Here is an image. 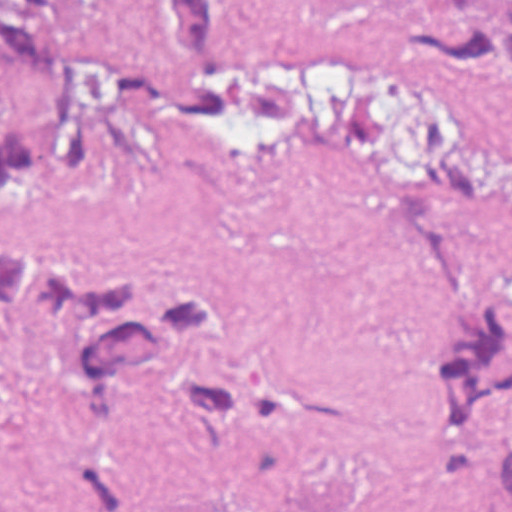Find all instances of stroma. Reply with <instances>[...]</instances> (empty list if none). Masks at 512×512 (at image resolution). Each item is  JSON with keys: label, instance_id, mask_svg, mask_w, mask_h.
<instances>
[{"label": "stroma", "instance_id": "1", "mask_svg": "<svg viewBox=\"0 0 512 512\" xmlns=\"http://www.w3.org/2000/svg\"><path fill=\"white\" fill-rule=\"evenodd\" d=\"M442 0H236L275 47L384 86L486 150L488 182L421 184L300 137L165 123L87 170L0 189V254L59 248L220 284L249 312L252 362L312 398L315 433L250 449L126 389L118 420L181 512H512L474 492L426 421V321L399 243L402 206L459 208L512 255V78L427 79L396 56L399 17ZM48 38L147 53L151 0H48ZM65 329L0 350V509L73 512L56 416ZM512 449V406L494 427Z\"/></svg>", "mask_w": 512, "mask_h": 512}]
</instances>
